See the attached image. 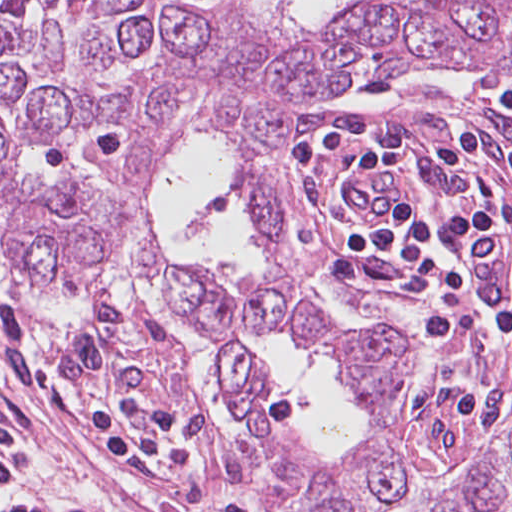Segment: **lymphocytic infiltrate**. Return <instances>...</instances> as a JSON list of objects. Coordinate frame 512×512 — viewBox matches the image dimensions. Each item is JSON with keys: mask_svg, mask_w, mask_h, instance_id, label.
I'll return each mask as SVG.
<instances>
[{"mask_svg": "<svg viewBox=\"0 0 512 512\" xmlns=\"http://www.w3.org/2000/svg\"><path fill=\"white\" fill-rule=\"evenodd\" d=\"M445 84L456 119L445 138L420 153L395 145L365 150L344 175L384 164H396L402 175L427 155L450 168L480 170V125L465 106L459 84ZM489 84L503 108L512 112V91ZM334 111L310 124L302 143V224L312 204L313 168ZM503 226L493 193L482 204L453 212L403 199L399 217L386 230L366 232L346 218L336 192L330 233L349 253L355 249L381 259L429 280L455 299L480 304L487 315L486 331L474 344L480 345L512 335V293L480 258V246ZM0 378L64 413L80 448L123 467L160 512H256L241 481L191 435L180 413L187 379L167 355L95 345L72 333L43 332L0 301ZM506 397L472 394L460 400L489 421ZM0 512L95 511L0 460Z\"/></svg>", "mask_w": 512, "mask_h": 512, "instance_id": "obj_1", "label": "lymphocytic infiltrate"}]
</instances>
